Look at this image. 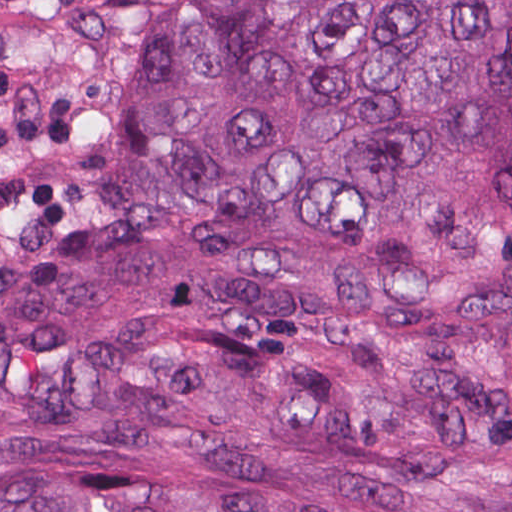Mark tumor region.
I'll return each instance as SVG.
<instances>
[{
  "label": "tumor region",
  "instance_id": "e687c5a6",
  "mask_svg": "<svg viewBox=\"0 0 512 512\" xmlns=\"http://www.w3.org/2000/svg\"><path fill=\"white\" fill-rule=\"evenodd\" d=\"M0 512H512V0H0Z\"/></svg>",
  "mask_w": 512,
  "mask_h": 512
}]
</instances>
